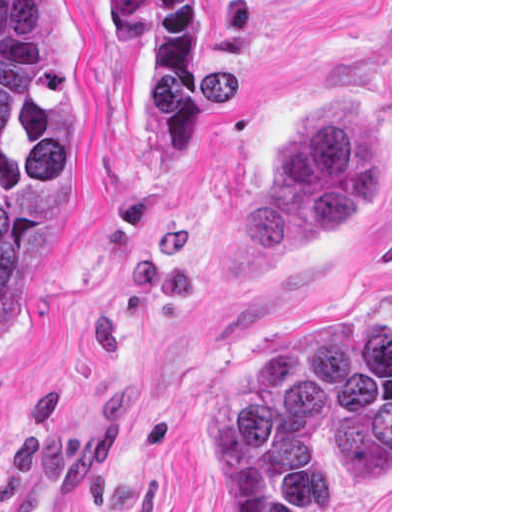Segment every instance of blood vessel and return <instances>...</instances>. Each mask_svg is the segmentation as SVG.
<instances>
[{
    "mask_svg": "<svg viewBox=\"0 0 512 512\" xmlns=\"http://www.w3.org/2000/svg\"><path fill=\"white\" fill-rule=\"evenodd\" d=\"M86 479L87 455L75 440L53 447L13 482L0 512H71Z\"/></svg>",
    "mask_w": 512,
    "mask_h": 512,
    "instance_id": "8fb6f2fc",
    "label": "blood vessel"
}]
</instances>
